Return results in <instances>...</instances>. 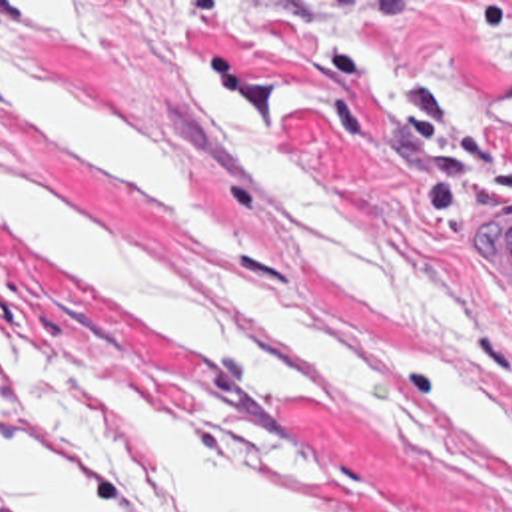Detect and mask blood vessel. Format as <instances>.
Listing matches in <instances>:
<instances>
[{
    "instance_id": "1",
    "label": "blood vessel",
    "mask_w": 512,
    "mask_h": 512,
    "mask_svg": "<svg viewBox=\"0 0 512 512\" xmlns=\"http://www.w3.org/2000/svg\"><path fill=\"white\" fill-rule=\"evenodd\" d=\"M489 108L512 118V78L485 92ZM485 256L512 294V220L485 228Z\"/></svg>"
}]
</instances>
